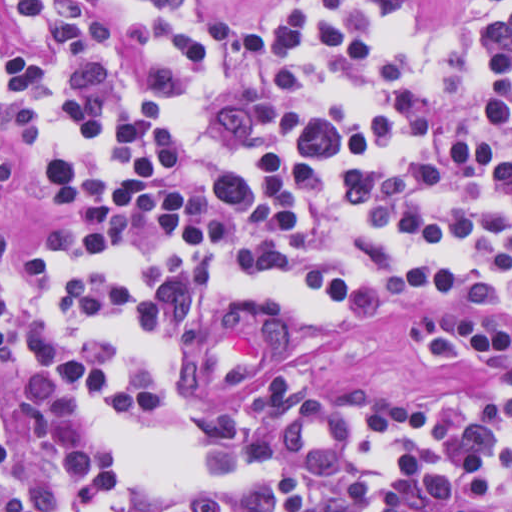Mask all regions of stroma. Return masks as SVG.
<instances>
[{
  "label": "stroma",
  "instance_id": "stroma-1",
  "mask_svg": "<svg viewBox=\"0 0 512 512\" xmlns=\"http://www.w3.org/2000/svg\"><path fill=\"white\" fill-rule=\"evenodd\" d=\"M1 1H512V0H0V512H1ZM491 142L512 161V121L493 132ZM13 210L6 240V263H28L34 239L70 218L37 164L24 151L9 166ZM441 302L418 300L405 313L375 322L301 323V346L244 380L216 391L213 403H244L261 394L280 374H307L333 398L355 385H377L414 403L455 390L473 389L478 369L466 363H438L420 357L410 334L412 323Z\"/></svg>",
  "mask_w": 512,
  "mask_h": 512
}]
</instances>
